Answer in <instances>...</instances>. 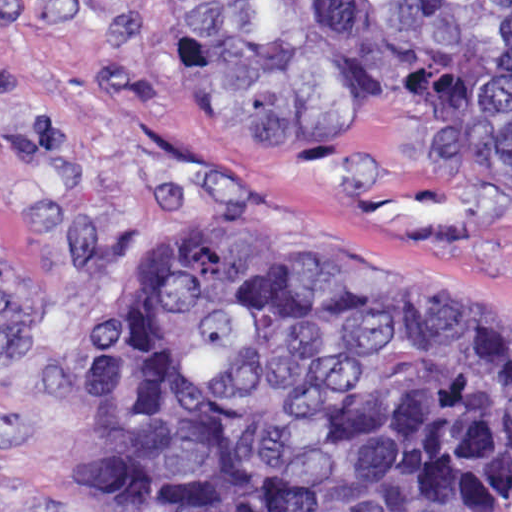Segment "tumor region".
Returning a JSON list of instances; mask_svg holds the SVG:
<instances>
[{"mask_svg":"<svg viewBox=\"0 0 512 512\" xmlns=\"http://www.w3.org/2000/svg\"><path fill=\"white\" fill-rule=\"evenodd\" d=\"M228 83L307 163H512V0H225ZM105 512H512V314L195 231L97 309Z\"/></svg>","mask_w":512,"mask_h":512,"instance_id":"tumor-region-1","label":"tumor region"}]
</instances>
